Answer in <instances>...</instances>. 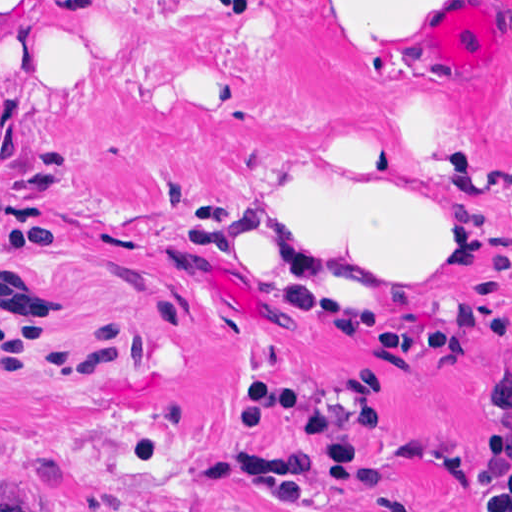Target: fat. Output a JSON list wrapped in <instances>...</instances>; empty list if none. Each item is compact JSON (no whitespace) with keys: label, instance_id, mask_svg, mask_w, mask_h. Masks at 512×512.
Returning <instances> with one entry per match:
<instances>
[{"label":"fat","instance_id":"obj_1","mask_svg":"<svg viewBox=\"0 0 512 512\" xmlns=\"http://www.w3.org/2000/svg\"><path fill=\"white\" fill-rule=\"evenodd\" d=\"M316 1L363 66L430 62L424 30L437 0ZM136 36L93 10L0 0V101L8 87H82L130 54ZM471 239L473 216L403 184L298 176L280 182L243 226L225 274L252 293L334 301L448 262Z\"/></svg>","mask_w":512,"mask_h":512}]
</instances>
